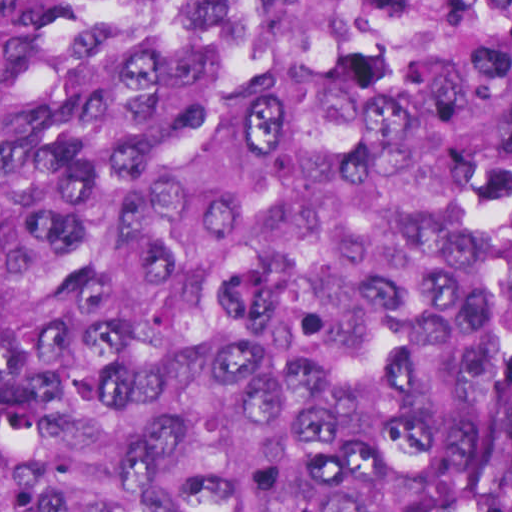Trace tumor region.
Returning <instances> with one entry per match:
<instances>
[{
	"label": "tumor region",
	"mask_w": 512,
	"mask_h": 512,
	"mask_svg": "<svg viewBox=\"0 0 512 512\" xmlns=\"http://www.w3.org/2000/svg\"><path fill=\"white\" fill-rule=\"evenodd\" d=\"M0 512H512V1H0Z\"/></svg>",
	"instance_id": "tumor-region-1"
}]
</instances>
